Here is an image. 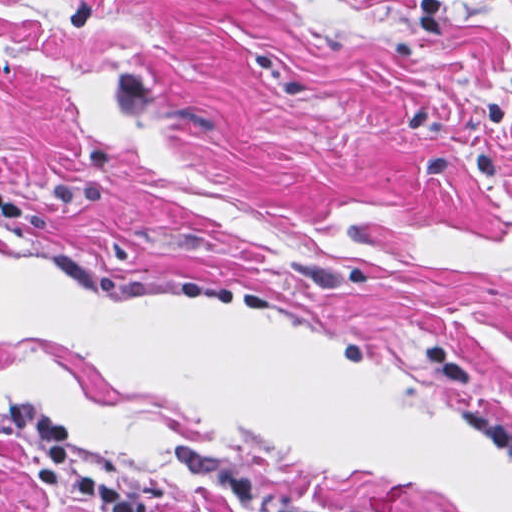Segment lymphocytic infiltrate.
<instances>
[{
  "label": "lymphocytic infiltrate",
  "mask_w": 512,
  "mask_h": 512,
  "mask_svg": "<svg viewBox=\"0 0 512 512\" xmlns=\"http://www.w3.org/2000/svg\"><path fill=\"white\" fill-rule=\"evenodd\" d=\"M23 206L0 192V218H19ZM424 370L436 379L455 420L491 449L512 458V421L491 402L477 372L450 346L431 339L411 341ZM0 434L27 443L29 465L47 492H61L83 512H159L146 496L88 476L79 463L78 432L55 408L0 406Z\"/></svg>",
  "instance_id": "1"
}]
</instances>
